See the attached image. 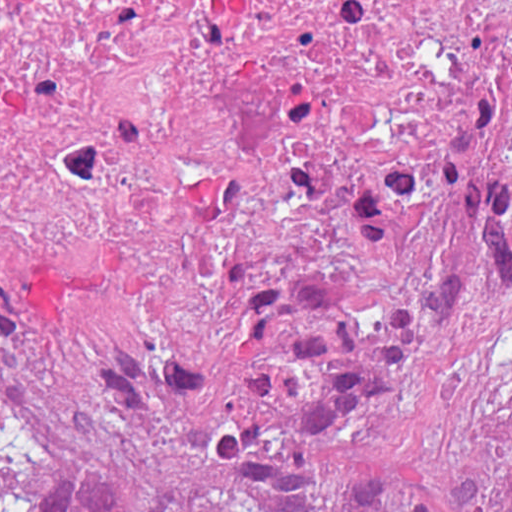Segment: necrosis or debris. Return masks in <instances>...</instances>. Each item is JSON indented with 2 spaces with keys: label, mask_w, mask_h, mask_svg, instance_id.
I'll use <instances>...</instances> for the list:
<instances>
[{
  "label": "necrosis or debris",
  "mask_w": 512,
  "mask_h": 512,
  "mask_svg": "<svg viewBox=\"0 0 512 512\" xmlns=\"http://www.w3.org/2000/svg\"><path fill=\"white\" fill-rule=\"evenodd\" d=\"M0 120L192 192L356 196L512 122V0H0Z\"/></svg>",
  "instance_id": "obj_1"
}]
</instances>
